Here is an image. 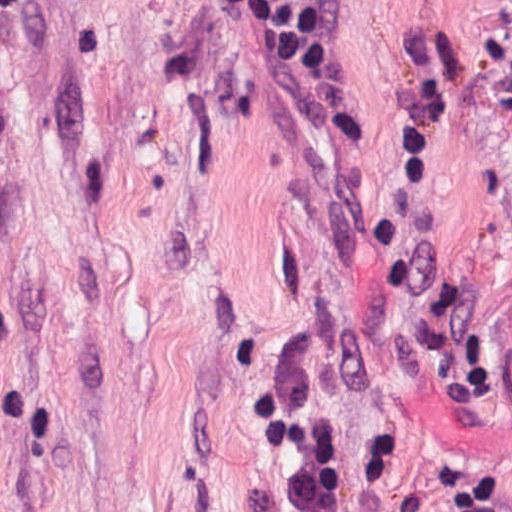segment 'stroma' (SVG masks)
I'll use <instances>...</instances> for the list:
<instances>
[{
	"label": "stroma",
	"instance_id": "obj_1",
	"mask_svg": "<svg viewBox=\"0 0 512 512\" xmlns=\"http://www.w3.org/2000/svg\"><path fill=\"white\" fill-rule=\"evenodd\" d=\"M283 363L341 512H512V0H342L318 94L231 0H0V512H290Z\"/></svg>",
	"mask_w": 512,
	"mask_h": 512
}]
</instances>
